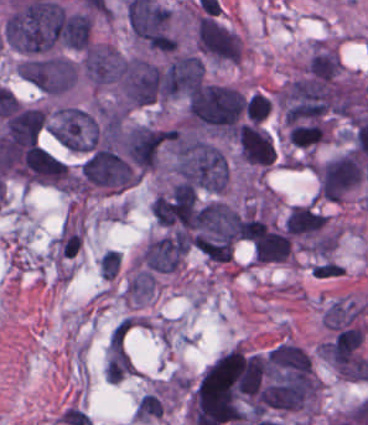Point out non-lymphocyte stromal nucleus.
<instances>
[{"mask_svg": "<svg viewBox=\"0 0 368 425\" xmlns=\"http://www.w3.org/2000/svg\"><path fill=\"white\" fill-rule=\"evenodd\" d=\"M341 70L340 58L327 46L311 48L301 73L316 80H334Z\"/></svg>", "mask_w": 368, "mask_h": 425, "instance_id": "1", "label": "non-lymphocyte stromal nucleus"}, {"mask_svg": "<svg viewBox=\"0 0 368 425\" xmlns=\"http://www.w3.org/2000/svg\"><path fill=\"white\" fill-rule=\"evenodd\" d=\"M364 305L350 299H335L321 314L326 327H342L363 311Z\"/></svg>", "mask_w": 368, "mask_h": 425, "instance_id": "2", "label": "non-lymphocyte stromal nucleus"}, {"mask_svg": "<svg viewBox=\"0 0 368 425\" xmlns=\"http://www.w3.org/2000/svg\"><path fill=\"white\" fill-rule=\"evenodd\" d=\"M155 287V280L149 270L138 269L127 281L122 298L142 302Z\"/></svg>", "mask_w": 368, "mask_h": 425, "instance_id": "3", "label": "non-lymphocyte stromal nucleus"}, {"mask_svg": "<svg viewBox=\"0 0 368 425\" xmlns=\"http://www.w3.org/2000/svg\"><path fill=\"white\" fill-rule=\"evenodd\" d=\"M244 110L249 119L260 121L270 110V99L254 92L249 95Z\"/></svg>", "mask_w": 368, "mask_h": 425, "instance_id": "4", "label": "non-lymphocyte stromal nucleus"}, {"mask_svg": "<svg viewBox=\"0 0 368 425\" xmlns=\"http://www.w3.org/2000/svg\"><path fill=\"white\" fill-rule=\"evenodd\" d=\"M120 254L118 250H104L99 259V272L107 278H112L119 267Z\"/></svg>", "mask_w": 368, "mask_h": 425, "instance_id": "5", "label": "non-lymphocyte stromal nucleus"}]
</instances>
